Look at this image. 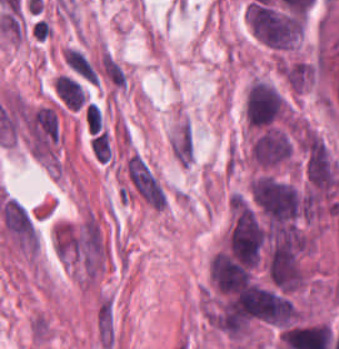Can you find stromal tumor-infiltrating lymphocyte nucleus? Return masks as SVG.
Returning a JSON list of instances; mask_svg holds the SVG:
<instances>
[{"label": "stromal tumor-infiltrating lymphocyte nucleus", "mask_w": 339, "mask_h": 349, "mask_svg": "<svg viewBox=\"0 0 339 349\" xmlns=\"http://www.w3.org/2000/svg\"><path fill=\"white\" fill-rule=\"evenodd\" d=\"M84 126L89 134L101 129L100 108L94 101H86L84 105Z\"/></svg>", "instance_id": "1"}]
</instances>
